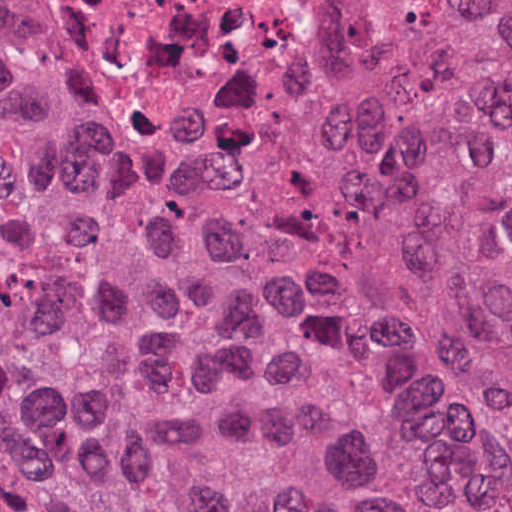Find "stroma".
<instances>
[{
  "label": "stroma",
  "mask_w": 512,
  "mask_h": 512,
  "mask_svg": "<svg viewBox=\"0 0 512 512\" xmlns=\"http://www.w3.org/2000/svg\"><path fill=\"white\" fill-rule=\"evenodd\" d=\"M345 42L346 15L343 1L336 0V29L333 43L315 73L332 61ZM0 76L46 126L93 153L106 156L124 164L143 168H170L182 163L136 162L98 146L65 111L56 93L39 82L29 64L16 55L3 50H0Z\"/></svg>",
  "instance_id": "obj_1"
}]
</instances>
